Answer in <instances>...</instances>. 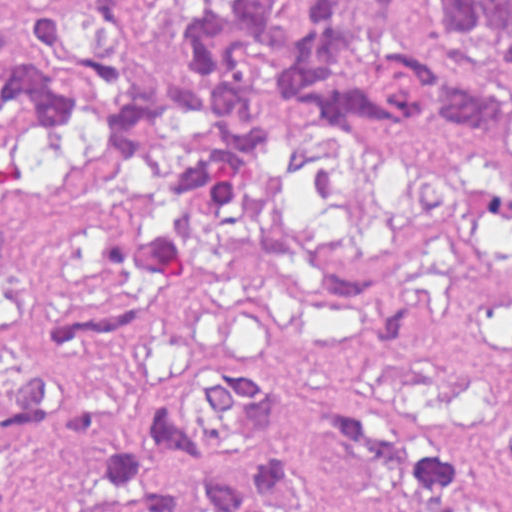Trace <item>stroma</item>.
Listing matches in <instances>:
<instances>
[{"label": "stroma", "mask_w": 512, "mask_h": 512, "mask_svg": "<svg viewBox=\"0 0 512 512\" xmlns=\"http://www.w3.org/2000/svg\"><path fill=\"white\" fill-rule=\"evenodd\" d=\"M146 1L157 60L175 49V24L167 0ZM89 2L0 0V26ZM251 113L287 124L267 188L172 278L122 267L116 227L152 197L108 136L90 129L82 149H57L0 133V377L42 372L48 336L81 314L146 308L148 337L84 387L140 469L191 512L187 476L137 413L148 388L215 366L308 379L366 423L431 437L468 466L477 512H512V115L490 141L434 120L418 133L378 120L320 130L287 93ZM0 497L2 512H122L88 483L84 459L3 429Z\"/></svg>", "instance_id": "35a3bbf8"}]
</instances>
